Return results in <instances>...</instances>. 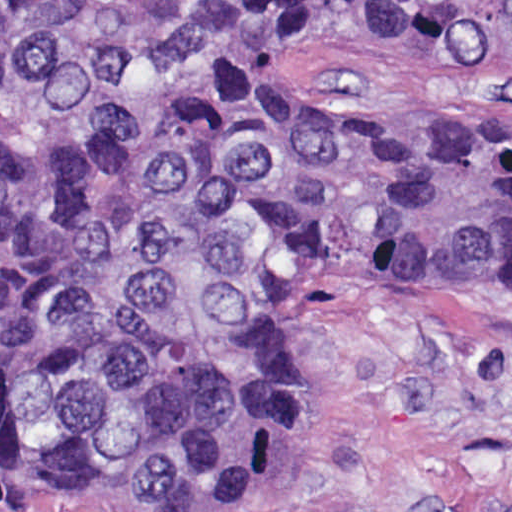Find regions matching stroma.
<instances>
[{
  "instance_id": "1",
  "label": "stroma",
  "mask_w": 512,
  "mask_h": 512,
  "mask_svg": "<svg viewBox=\"0 0 512 512\" xmlns=\"http://www.w3.org/2000/svg\"><path fill=\"white\" fill-rule=\"evenodd\" d=\"M306 86L362 123H473L512 116V55L338 17ZM0 512H512V287H332L311 398L220 506Z\"/></svg>"
}]
</instances>
